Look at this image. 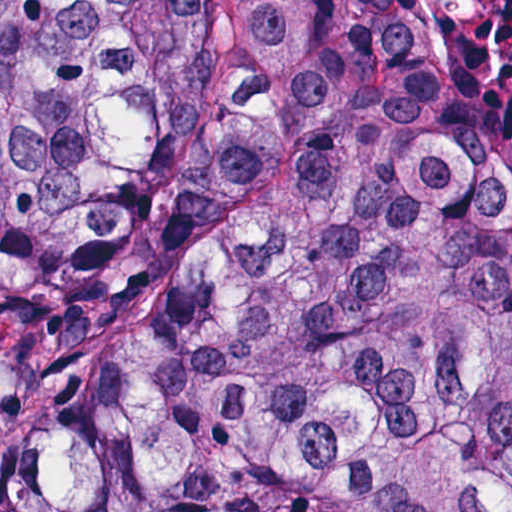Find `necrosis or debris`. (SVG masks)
I'll use <instances>...</instances> for the list:
<instances>
[{
    "instance_id": "necrosis-or-debris-1",
    "label": "necrosis or debris",
    "mask_w": 512,
    "mask_h": 512,
    "mask_svg": "<svg viewBox=\"0 0 512 512\" xmlns=\"http://www.w3.org/2000/svg\"><path fill=\"white\" fill-rule=\"evenodd\" d=\"M446 70L489 102L512 103V0H412Z\"/></svg>"
}]
</instances>
